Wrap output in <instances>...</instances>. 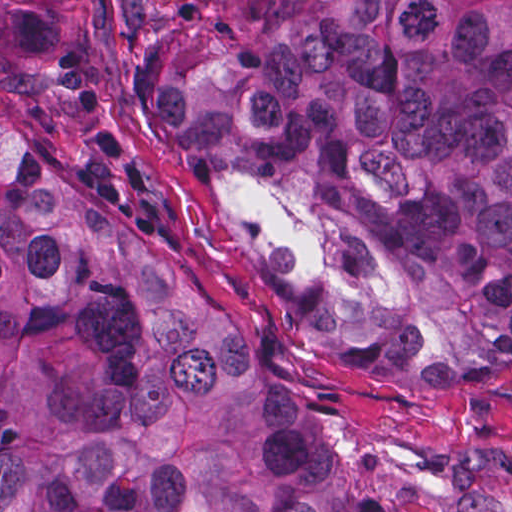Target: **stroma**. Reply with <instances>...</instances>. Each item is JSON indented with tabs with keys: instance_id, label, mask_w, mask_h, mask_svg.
Masks as SVG:
<instances>
[{
	"instance_id": "obj_1",
	"label": "stroma",
	"mask_w": 512,
	"mask_h": 512,
	"mask_svg": "<svg viewBox=\"0 0 512 512\" xmlns=\"http://www.w3.org/2000/svg\"><path fill=\"white\" fill-rule=\"evenodd\" d=\"M85 76L131 177L182 230L204 298L241 343L257 345L299 405L322 451L360 463L375 512H512V463L463 448L512 438V381L417 385L331 374L250 280L212 218L140 117L128 90V0H64ZM0 512H1V0H0Z\"/></svg>"
}]
</instances>
